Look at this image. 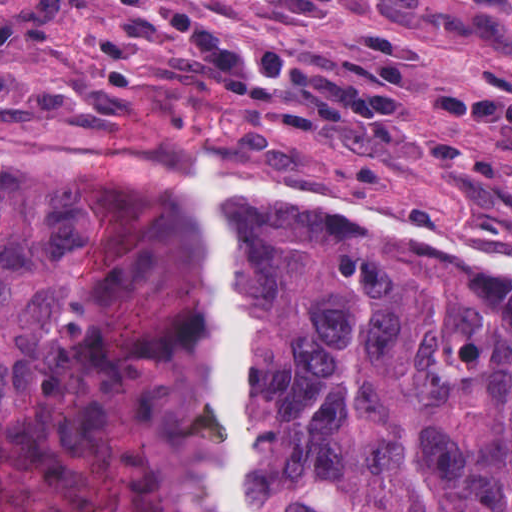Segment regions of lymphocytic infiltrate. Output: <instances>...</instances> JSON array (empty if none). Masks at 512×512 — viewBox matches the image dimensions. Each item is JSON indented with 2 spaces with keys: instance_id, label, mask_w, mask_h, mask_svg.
I'll list each match as a JSON object with an SVG mask.
<instances>
[{
  "instance_id": "obj_1",
  "label": "lymphocytic infiltrate",
  "mask_w": 512,
  "mask_h": 512,
  "mask_svg": "<svg viewBox=\"0 0 512 512\" xmlns=\"http://www.w3.org/2000/svg\"><path fill=\"white\" fill-rule=\"evenodd\" d=\"M149 31L167 28L239 97L327 126L363 127L397 139L413 133L418 46L398 25L369 36V53L346 58L330 46L261 50L228 33L203 0H114ZM269 20H321L359 13L376 0H220ZM68 0H0V41L16 46L49 35ZM506 25L512 30V6ZM428 121H467L493 144H512V94L496 88L433 87L418 92ZM443 164L485 186L491 209L512 216V160L481 159L439 136Z\"/></svg>"
}]
</instances>
